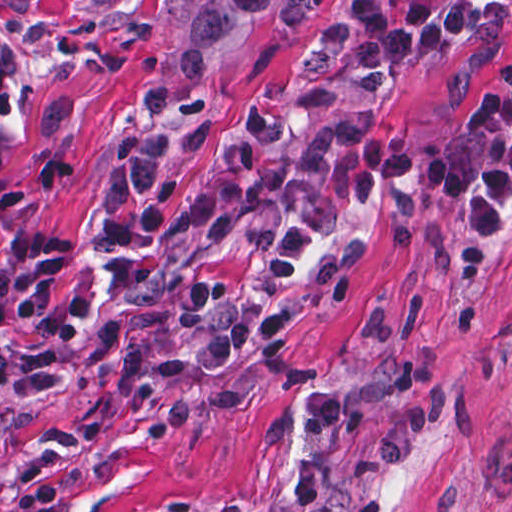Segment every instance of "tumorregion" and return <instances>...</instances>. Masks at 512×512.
<instances>
[{"label":"tumor region","mask_w":512,"mask_h":512,"mask_svg":"<svg viewBox=\"0 0 512 512\" xmlns=\"http://www.w3.org/2000/svg\"><path fill=\"white\" fill-rule=\"evenodd\" d=\"M174 46L164 72L177 82H202L218 65L230 37L275 0H165Z\"/></svg>","instance_id":"e687c5a6"}]
</instances>
